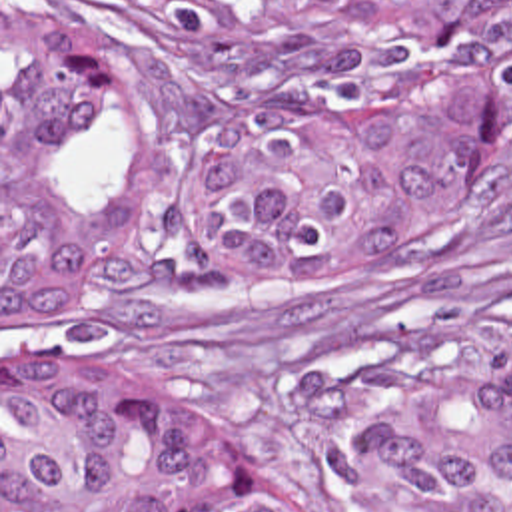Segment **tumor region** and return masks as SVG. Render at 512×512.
I'll return each instance as SVG.
<instances>
[{"label":"tumor region","instance_id":"obj_1","mask_svg":"<svg viewBox=\"0 0 512 512\" xmlns=\"http://www.w3.org/2000/svg\"><path fill=\"white\" fill-rule=\"evenodd\" d=\"M220 98L144 88L124 46L2 0V329L104 275L72 175L90 98L186 155L196 257L236 285H349L429 253L512 139V0H112ZM351 512H512V347L381 387ZM2 512H329L252 473L178 401L2 369Z\"/></svg>","mask_w":512,"mask_h":512}]
</instances>
